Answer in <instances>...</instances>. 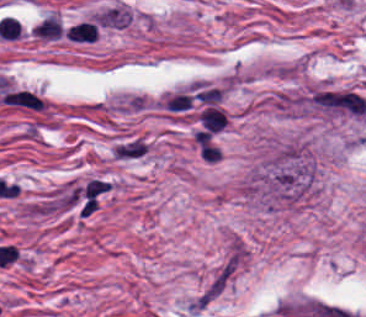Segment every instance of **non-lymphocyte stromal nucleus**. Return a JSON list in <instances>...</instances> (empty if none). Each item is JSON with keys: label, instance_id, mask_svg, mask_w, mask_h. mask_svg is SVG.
Masks as SVG:
<instances>
[{"label": "non-lymphocyte stromal nucleus", "instance_id": "non-lymphocyte-stromal-nucleus-1", "mask_svg": "<svg viewBox=\"0 0 366 317\" xmlns=\"http://www.w3.org/2000/svg\"><path fill=\"white\" fill-rule=\"evenodd\" d=\"M245 254L244 247L228 246L208 273L196 298L198 304L203 307L211 303L228 288L243 268Z\"/></svg>", "mask_w": 366, "mask_h": 317}, {"label": "non-lymphocyte stromal nucleus", "instance_id": "non-lymphocyte-stromal-nucleus-2", "mask_svg": "<svg viewBox=\"0 0 366 317\" xmlns=\"http://www.w3.org/2000/svg\"><path fill=\"white\" fill-rule=\"evenodd\" d=\"M149 147L148 138L138 134H125L112 143L110 159L123 162L137 160L147 154Z\"/></svg>", "mask_w": 366, "mask_h": 317}, {"label": "non-lymphocyte stromal nucleus", "instance_id": "non-lymphocyte-stromal-nucleus-3", "mask_svg": "<svg viewBox=\"0 0 366 317\" xmlns=\"http://www.w3.org/2000/svg\"><path fill=\"white\" fill-rule=\"evenodd\" d=\"M7 104L12 106L42 109L44 100L39 95L27 89H14L6 91L0 96Z\"/></svg>", "mask_w": 366, "mask_h": 317}]
</instances>
